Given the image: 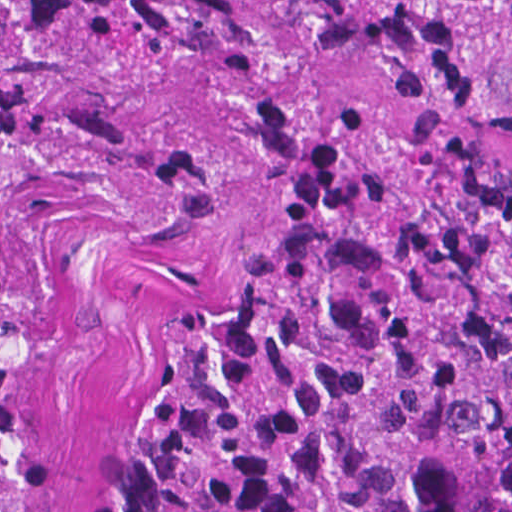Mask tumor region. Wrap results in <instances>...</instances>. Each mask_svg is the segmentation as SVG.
<instances>
[{
  "mask_svg": "<svg viewBox=\"0 0 512 512\" xmlns=\"http://www.w3.org/2000/svg\"><path fill=\"white\" fill-rule=\"evenodd\" d=\"M33 174L250 206L91 512H512V0H0V300Z\"/></svg>",
  "mask_w": 512,
  "mask_h": 512,
  "instance_id": "tumor-region-1",
  "label": "tumor region"
}]
</instances>
